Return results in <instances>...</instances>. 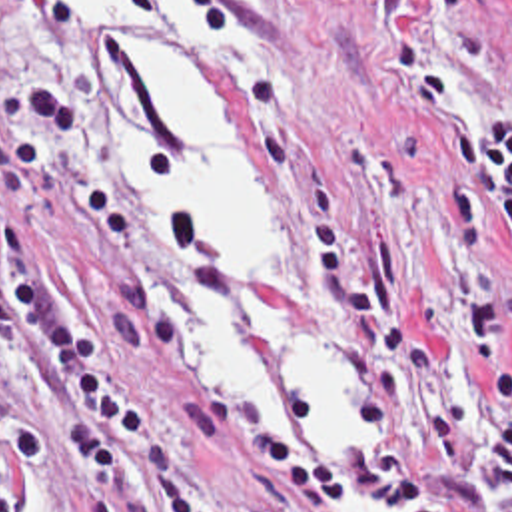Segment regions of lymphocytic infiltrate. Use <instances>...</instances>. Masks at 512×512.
Wrapping results in <instances>:
<instances>
[{
	"label": "lymphocytic infiltrate",
	"mask_w": 512,
	"mask_h": 512,
	"mask_svg": "<svg viewBox=\"0 0 512 512\" xmlns=\"http://www.w3.org/2000/svg\"><path fill=\"white\" fill-rule=\"evenodd\" d=\"M79 133L73 102L49 84H23L0 133V185L13 213H0V329L41 395L65 425L53 435L75 467L119 477L147 473L173 491L179 512H223L219 499L167 425L111 373L87 315L45 285L35 227L55 167ZM446 169L430 181V219L444 281L494 389V407L460 471L430 473V487L458 512H512V361L494 287L474 249L484 213L498 215L512 243V110L442 119ZM7 447L41 461L45 433L0 407V512L7 493Z\"/></svg>",
	"instance_id": "1"
}]
</instances>
